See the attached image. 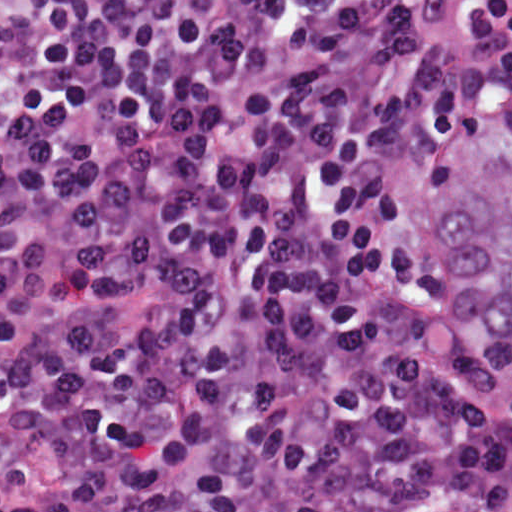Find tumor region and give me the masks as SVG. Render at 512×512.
<instances>
[{
  "label": "tumor region",
  "mask_w": 512,
  "mask_h": 512,
  "mask_svg": "<svg viewBox=\"0 0 512 512\" xmlns=\"http://www.w3.org/2000/svg\"><path fill=\"white\" fill-rule=\"evenodd\" d=\"M439 273L512 388V127L480 154L443 245Z\"/></svg>",
  "instance_id": "obj_1"
}]
</instances>
